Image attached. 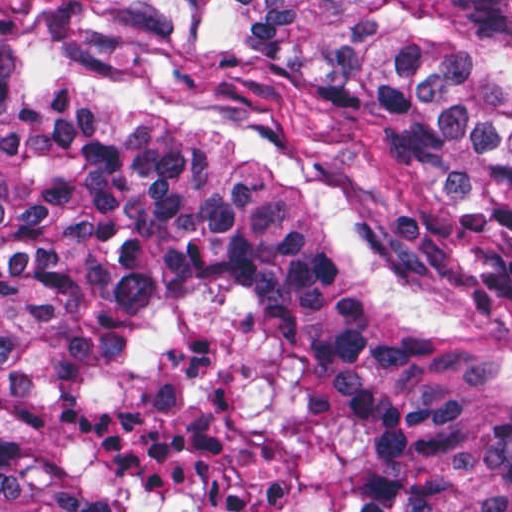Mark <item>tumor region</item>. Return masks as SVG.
Returning <instances> with one entry per match:
<instances>
[{
	"label": "tumor region",
	"instance_id": "tumor-region-1",
	"mask_svg": "<svg viewBox=\"0 0 512 512\" xmlns=\"http://www.w3.org/2000/svg\"><path fill=\"white\" fill-rule=\"evenodd\" d=\"M0 512H512V0H0Z\"/></svg>",
	"mask_w": 512,
	"mask_h": 512
}]
</instances>
